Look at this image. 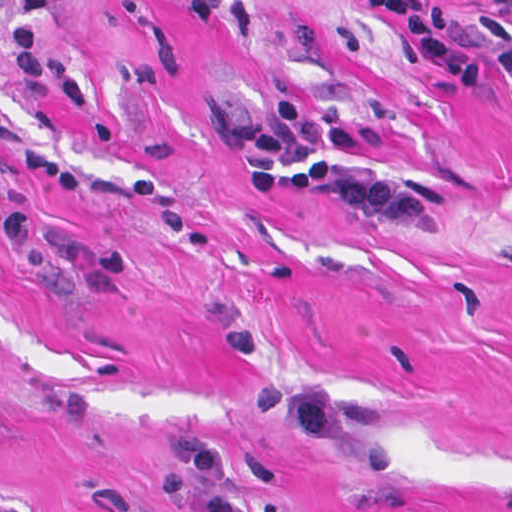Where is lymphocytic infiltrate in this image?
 <instances>
[{
  "mask_svg": "<svg viewBox=\"0 0 512 512\" xmlns=\"http://www.w3.org/2000/svg\"><path fill=\"white\" fill-rule=\"evenodd\" d=\"M396 18L410 42L460 85L479 86L483 71L460 35L474 41L494 71L512 75V18L478 17L458 7L424 6L410 0H367ZM512 11V0H484ZM58 0H19L7 34L9 70L33 93L58 103L89 108L94 85L81 69L46 53L41 39L43 14ZM300 143H320L348 150L352 134L316 113L303 99L288 95L268 107L258 125L251 154L250 185L264 197L317 195L338 206L391 223H427L432 198L422 188L393 179L348 174L333 156L296 160ZM0 238L21 252L36 251V220L13 212L0 201Z\"/></svg>",
  "mask_w": 512,
  "mask_h": 512,
  "instance_id": "1",
  "label": "lymphocytic infiltrate"
}]
</instances>
